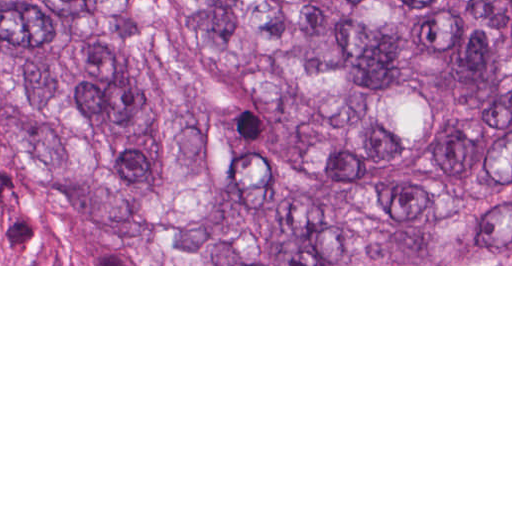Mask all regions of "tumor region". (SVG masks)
Instances as JSON below:
<instances>
[{"mask_svg":"<svg viewBox=\"0 0 512 512\" xmlns=\"http://www.w3.org/2000/svg\"><path fill=\"white\" fill-rule=\"evenodd\" d=\"M0 137L180 264L512 263V0H0Z\"/></svg>","mask_w":512,"mask_h":512,"instance_id":"e687c5a6","label":"tumor region"}]
</instances>
